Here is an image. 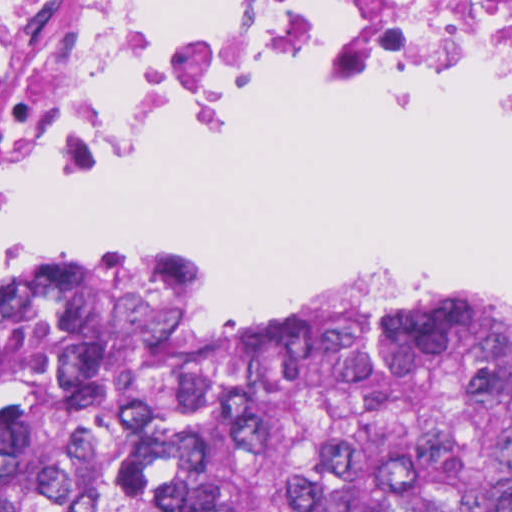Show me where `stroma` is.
<instances>
[{
	"label": "stroma",
	"instance_id": "35a3bbf8",
	"mask_svg": "<svg viewBox=\"0 0 512 512\" xmlns=\"http://www.w3.org/2000/svg\"><path fill=\"white\" fill-rule=\"evenodd\" d=\"M275 96L259 92H232L216 94L36 189L0 207V228L11 219L31 208L58 189L82 178L100 163L136 142L151 135L174 118L201 109L237 104ZM86 272H0V293L11 295L63 288ZM378 283H412L450 291H512V273L474 280H439L416 276H346L326 280L276 307L232 308L236 314L263 316L279 313L328 298L362 289Z\"/></svg>",
	"mask_w": 512,
	"mask_h": 512
}]
</instances>
